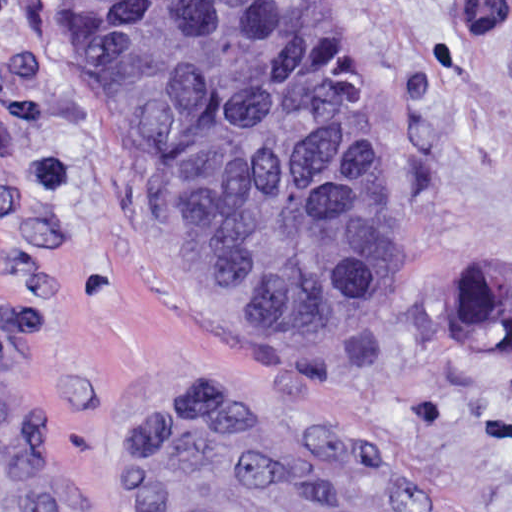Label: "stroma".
<instances>
[{
	"label": "stroma",
	"mask_w": 512,
	"mask_h": 512,
	"mask_svg": "<svg viewBox=\"0 0 512 512\" xmlns=\"http://www.w3.org/2000/svg\"><path fill=\"white\" fill-rule=\"evenodd\" d=\"M324 1L417 291L365 330L260 338L112 177L62 0H0V512H155L152 442L212 396L338 430L432 512H512V358L464 354L447 310L467 264L512 278V0L480 57L454 0Z\"/></svg>",
	"instance_id": "35a3bbf8"
}]
</instances>
